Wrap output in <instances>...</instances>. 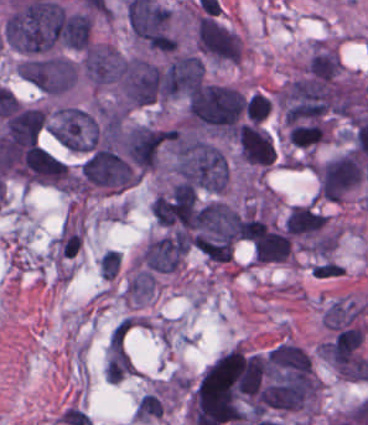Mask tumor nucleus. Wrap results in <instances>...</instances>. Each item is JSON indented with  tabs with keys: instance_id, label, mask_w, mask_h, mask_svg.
Here are the masks:
<instances>
[{
	"instance_id": "obj_8",
	"label": "tumor nucleus",
	"mask_w": 368,
	"mask_h": 425,
	"mask_svg": "<svg viewBox=\"0 0 368 425\" xmlns=\"http://www.w3.org/2000/svg\"><path fill=\"white\" fill-rule=\"evenodd\" d=\"M239 156L244 160L270 164L275 150L269 132L252 124H243L237 128Z\"/></svg>"
},
{
	"instance_id": "obj_4",
	"label": "tumor nucleus",
	"mask_w": 368,
	"mask_h": 425,
	"mask_svg": "<svg viewBox=\"0 0 368 425\" xmlns=\"http://www.w3.org/2000/svg\"><path fill=\"white\" fill-rule=\"evenodd\" d=\"M17 74L41 93L61 95L73 88L78 64L59 54H27Z\"/></svg>"
},
{
	"instance_id": "obj_2",
	"label": "tumor nucleus",
	"mask_w": 368,
	"mask_h": 425,
	"mask_svg": "<svg viewBox=\"0 0 368 425\" xmlns=\"http://www.w3.org/2000/svg\"><path fill=\"white\" fill-rule=\"evenodd\" d=\"M245 99L231 85L202 84L190 90L187 112L200 124L229 129L243 112Z\"/></svg>"
},
{
	"instance_id": "obj_7",
	"label": "tumor nucleus",
	"mask_w": 368,
	"mask_h": 425,
	"mask_svg": "<svg viewBox=\"0 0 368 425\" xmlns=\"http://www.w3.org/2000/svg\"><path fill=\"white\" fill-rule=\"evenodd\" d=\"M81 66L88 83L100 88L118 76L121 52L108 43L92 41L83 50Z\"/></svg>"
},
{
	"instance_id": "obj_5",
	"label": "tumor nucleus",
	"mask_w": 368,
	"mask_h": 425,
	"mask_svg": "<svg viewBox=\"0 0 368 425\" xmlns=\"http://www.w3.org/2000/svg\"><path fill=\"white\" fill-rule=\"evenodd\" d=\"M194 41L202 57L216 62H238L242 43L235 31L213 16L195 20Z\"/></svg>"
},
{
	"instance_id": "obj_6",
	"label": "tumor nucleus",
	"mask_w": 368,
	"mask_h": 425,
	"mask_svg": "<svg viewBox=\"0 0 368 425\" xmlns=\"http://www.w3.org/2000/svg\"><path fill=\"white\" fill-rule=\"evenodd\" d=\"M314 171L321 197L331 200H340L362 178L359 158L348 150L321 161L315 165Z\"/></svg>"
},
{
	"instance_id": "obj_1",
	"label": "tumor nucleus",
	"mask_w": 368,
	"mask_h": 425,
	"mask_svg": "<svg viewBox=\"0 0 368 425\" xmlns=\"http://www.w3.org/2000/svg\"><path fill=\"white\" fill-rule=\"evenodd\" d=\"M171 166L181 181L212 191H222L229 174L224 151L196 131L172 134Z\"/></svg>"
},
{
	"instance_id": "obj_3",
	"label": "tumor nucleus",
	"mask_w": 368,
	"mask_h": 425,
	"mask_svg": "<svg viewBox=\"0 0 368 425\" xmlns=\"http://www.w3.org/2000/svg\"><path fill=\"white\" fill-rule=\"evenodd\" d=\"M48 131L73 151H88L99 138V123L93 109L61 103L48 113Z\"/></svg>"
}]
</instances>
